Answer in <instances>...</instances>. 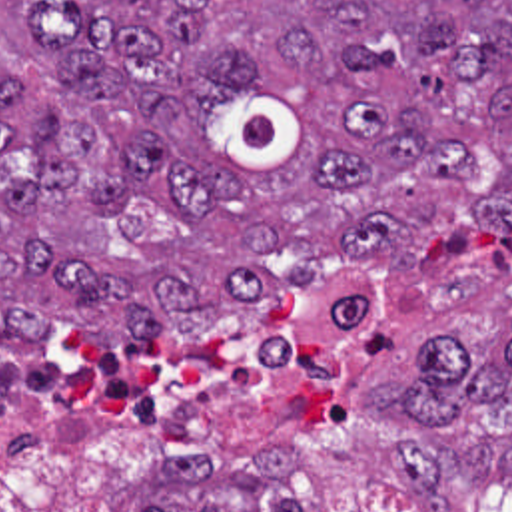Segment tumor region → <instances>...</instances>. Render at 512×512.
Listing matches in <instances>:
<instances>
[{
	"instance_id": "e687c5a6",
	"label": "tumor region",
	"mask_w": 512,
	"mask_h": 512,
	"mask_svg": "<svg viewBox=\"0 0 512 512\" xmlns=\"http://www.w3.org/2000/svg\"><path fill=\"white\" fill-rule=\"evenodd\" d=\"M512 229V0H0V329L103 343ZM366 405L418 512L512 480V311ZM147 512H167L153 506ZM201 512H217L203 508Z\"/></svg>"
}]
</instances>
